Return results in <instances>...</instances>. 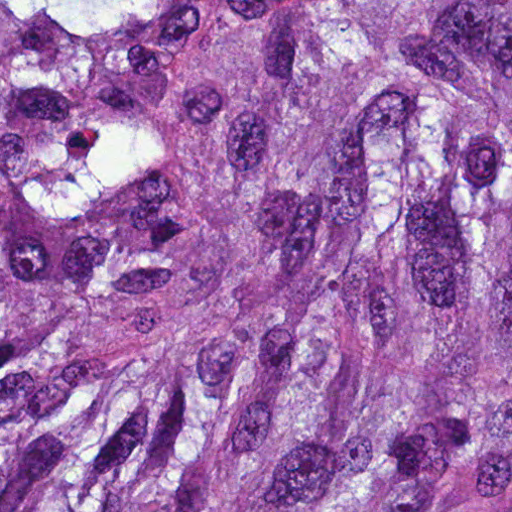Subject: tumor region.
<instances>
[{
    "mask_svg": "<svg viewBox=\"0 0 512 512\" xmlns=\"http://www.w3.org/2000/svg\"><path fill=\"white\" fill-rule=\"evenodd\" d=\"M1 512H512V0H1Z\"/></svg>",
    "mask_w": 512,
    "mask_h": 512,
    "instance_id": "e687c5a6",
    "label": "tumor region"
}]
</instances>
